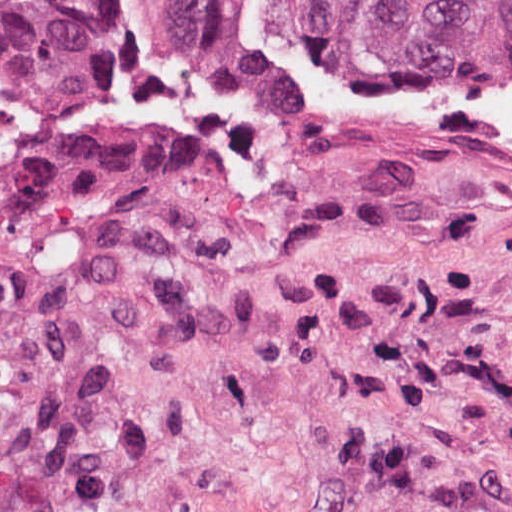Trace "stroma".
Segmentation results:
<instances>
[{
    "label": "stroma",
    "instance_id": "obj_1",
    "mask_svg": "<svg viewBox=\"0 0 512 512\" xmlns=\"http://www.w3.org/2000/svg\"><path fill=\"white\" fill-rule=\"evenodd\" d=\"M0 512H512V162L306 140L117 0L0 154Z\"/></svg>",
    "mask_w": 512,
    "mask_h": 512
}]
</instances>
